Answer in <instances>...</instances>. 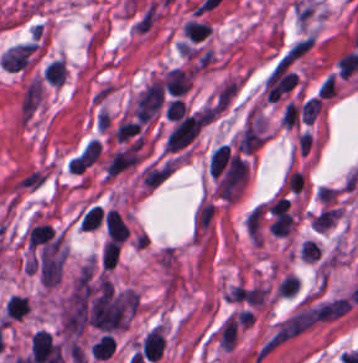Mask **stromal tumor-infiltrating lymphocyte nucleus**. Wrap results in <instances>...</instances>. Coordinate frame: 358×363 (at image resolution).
Wrapping results in <instances>:
<instances>
[{
  "label": "stromal tumor-infiltrating lymphocyte nucleus",
  "instance_id": "bc302bb0",
  "mask_svg": "<svg viewBox=\"0 0 358 363\" xmlns=\"http://www.w3.org/2000/svg\"><path fill=\"white\" fill-rule=\"evenodd\" d=\"M165 339L162 328L153 327L141 342V352L145 359H158L164 350Z\"/></svg>",
  "mask_w": 358,
  "mask_h": 363
},
{
  "label": "stromal tumor-infiltrating lymphocyte nucleus",
  "instance_id": "52c7bb5b",
  "mask_svg": "<svg viewBox=\"0 0 358 363\" xmlns=\"http://www.w3.org/2000/svg\"><path fill=\"white\" fill-rule=\"evenodd\" d=\"M164 87L169 95H181L186 93L190 86L189 72L179 69H169L163 78Z\"/></svg>",
  "mask_w": 358,
  "mask_h": 363
},
{
  "label": "stromal tumor-infiltrating lymphocyte nucleus",
  "instance_id": "3290ff9b",
  "mask_svg": "<svg viewBox=\"0 0 358 363\" xmlns=\"http://www.w3.org/2000/svg\"><path fill=\"white\" fill-rule=\"evenodd\" d=\"M28 243L33 249L56 246L51 225L49 223H35L28 233Z\"/></svg>",
  "mask_w": 358,
  "mask_h": 363
},
{
  "label": "stromal tumor-infiltrating lymphocyte nucleus",
  "instance_id": "abfb95fc",
  "mask_svg": "<svg viewBox=\"0 0 358 363\" xmlns=\"http://www.w3.org/2000/svg\"><path fill=\"white\" fill-rule=\"evenodd\" d=\"M66 74L65 62L61 58H54L49 62L43 72L44 78L49 83L61 84Z\"/></svg>",
  "mask_w": 358,
  "mask_h": 363
},
{
  "label": "stromal tumor-infiltrating lymphocyte nucleus",
  "instance_id": "9ea309e8",
  "mask_svg": "<svg viewBox=\"0 0 358 363\" xmlns=\"http://www.w3.org/2000/svg\"><path fill=\"white\" fill-rule=\"evenodd\" d=\"M358 67V52L349 51L337 62L338 74L343 77L350 75Z\"/></svg>",
  "mask_w": 358,
  "mask_h": 363
},
{
  "label": "stromal tumor-infiltrating lymphocyte nucleus",
  "instance_id": "f3e2335f",
  "mask_svg": "<svg viewBox=\"0 0 358 363\" xmlns=\"http://www.w3.org/2000/svg\"><path fill=\"white\" fill-rule=\"evenodd\" d=\"M104 215L103 209L94 204L86 211L81 221L83 229H96L101 224Z\"/></svg>",
  "mask_w": 358,
  "mask_h": 363
}]
</instances>
